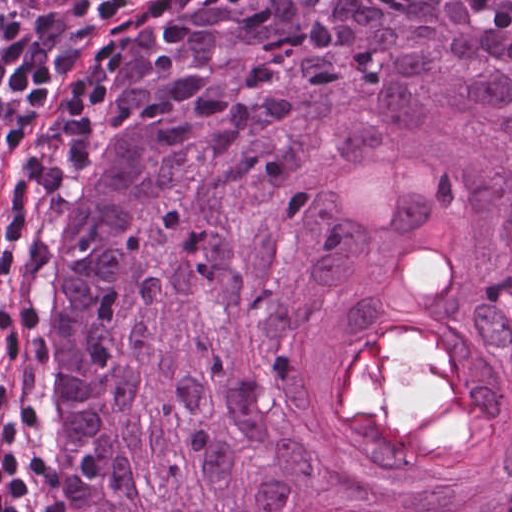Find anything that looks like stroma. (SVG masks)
Wrapping results in <instances>:
<instances>
[{
    "label": "stroma",
    "mask_w": 512,
    "mask_h": 512,
    "mask_svg": "<svg viewBox=\"0 0 512 512\" xmlns=\"http://www.w3.org/2000/svg\"><path fill=\"white\" fill-rule=\"evenodd\" d=\"M202 0H113L96 14L78 42L74 62L34 126L58 162L53 181L57 230L42 275L45 305L61 253L85 226L104 181L118 112L134 74L153 42ZM40 13V12H20ZM22 320L0 350V361L16 340ZM12 427L38 458V405L34 419L0 405V445Z\"/></svg>",
    "instance_id": "35a3bbf8"
}]
</instances>
